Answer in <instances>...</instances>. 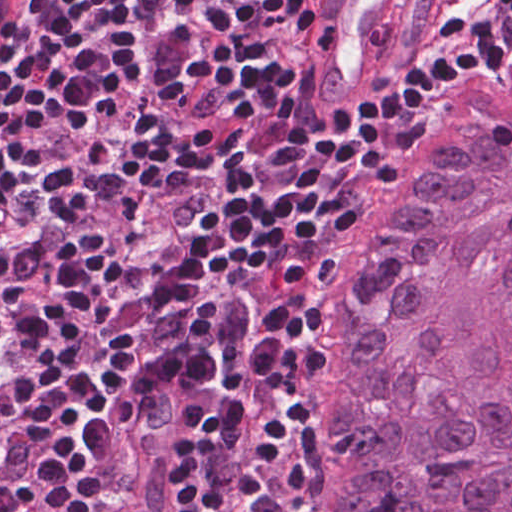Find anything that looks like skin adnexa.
<instances>
[{
    "instance_id": "bc48264e",
    "label": "skin adnexa",
    "mask_w": 512,
    "mask_h": 512,
    "mask_svg": "<svg viewBox=\"0 0 512 512\" xmlns=\"http://www.w3.org/2000/svg\"><path fill=\"white\" fill-rule=\"evenodd\" d=\"M298 512H512V71L423 121L336 261Z\"/></svg>"
}]
</instances>
